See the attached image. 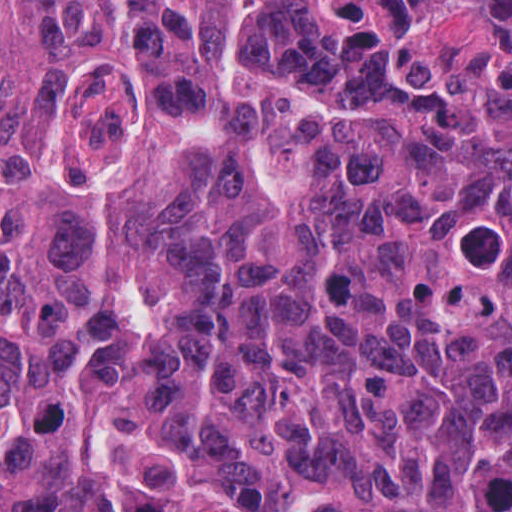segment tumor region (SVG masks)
Masks as SVG:
<instances>
[{"label":"tumor region","mask_w":512,"mask_h":512,"mask_svg":"<svg viewBox=\"0 0 512 512\" xmlns=\"http://www.w3.org/2000/svg\"><path fill=\"white\" fill-rule=\"evenodd\" d=\"M0 512H512V1H0Z\"/></svg>","instance_id":"1"}]
</instances>
